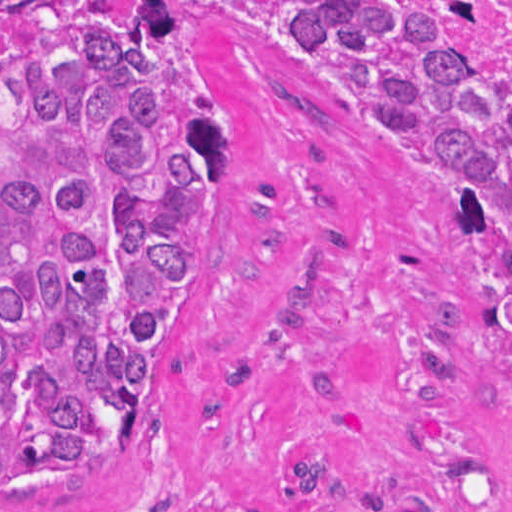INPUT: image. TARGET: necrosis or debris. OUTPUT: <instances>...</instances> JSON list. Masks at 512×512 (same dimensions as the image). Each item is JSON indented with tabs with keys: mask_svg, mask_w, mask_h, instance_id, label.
<instances>
[{
	"mask_svg": "<svg viewBox=\"0 0 512 512\" xmlns=\"http://www.w3.org/2000/svg\"><path fill=\"white\" fill-rule=\"evenodd\" d=\"M468 25L512 40V1H471Z\"/></svg>",
	"mask_w": 512,
	"mask_h": 512,
	"instance_id": "obj_1",
	"label": "necrosis or debris"
}]
</instances>
